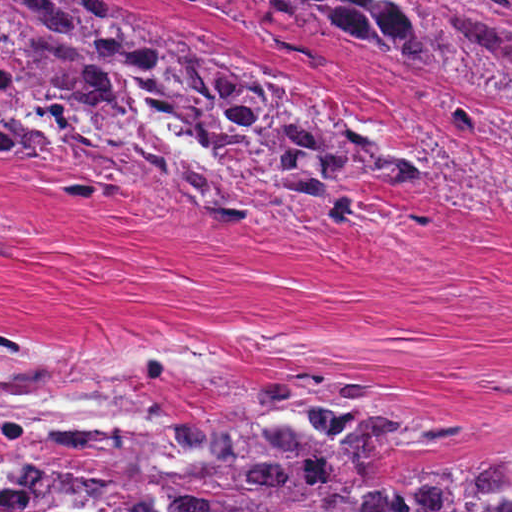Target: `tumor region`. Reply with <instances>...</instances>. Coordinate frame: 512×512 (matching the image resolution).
<instances>
[{"instance_id":"tumor-region-1","label":"tumor region","mask_w":512,"mask_h":512,"mask_svg":"<svg viewBox=\"0 0 512 512\" xmlns=\"http://www.w3.org/2000/svg\"><path fill=\"white\" fill-rule=\"evenodd\" d=\"M258 1L512 105V0ZM27 145L57 152L75 194L143 185L191 219L314 242L350 224L360 185L417 180L341 98L106 0H0V148ZM384 382L314 367L205 384L153 337L40 339L0 318V512H512V445L395 463L482 452L506 416L369 406Z\"/></svg>"}]
</instances>
